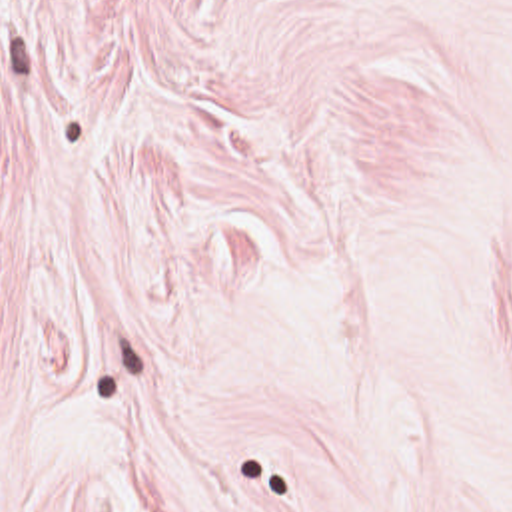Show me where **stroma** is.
<instances>
[{
  "label": "stroma",
  "instance_id": "stroma-1",
  "mask_svg": "<svg viewBox=\"0 0 512 512\" xmlns=\"http://www.w3.org/2000/svg\"><path fill=\"white\" fill-rule=\"evenodd\" d=\"M0 512H512V0H0Z\"/></svg>",
  "mask_w": 512,
  "mask_h": 512
}]
</instances>
